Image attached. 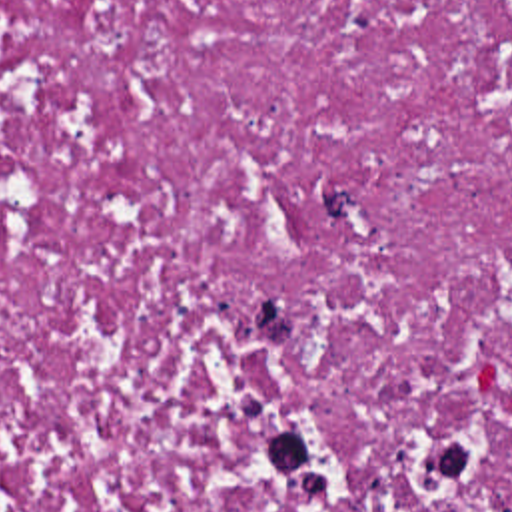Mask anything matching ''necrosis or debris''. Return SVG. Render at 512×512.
I'll list each match as a JSON object with an SVG mask.
<instances>
[{
  "mask_svg": "<svg viewBox=\"0 0 512 512\" xmlns=\"http://www.w3.org/2000/svg\"><path fill=\"white\" fill-rule=\"evenodd\" d=\"M0 512H512V0H0Z\"/></svg>",
  "mask_w": 512,
  "mask_h": 512,
  "instance_id": "obj_1",
  "label": "necrosis or debris"
}]
</instances>
